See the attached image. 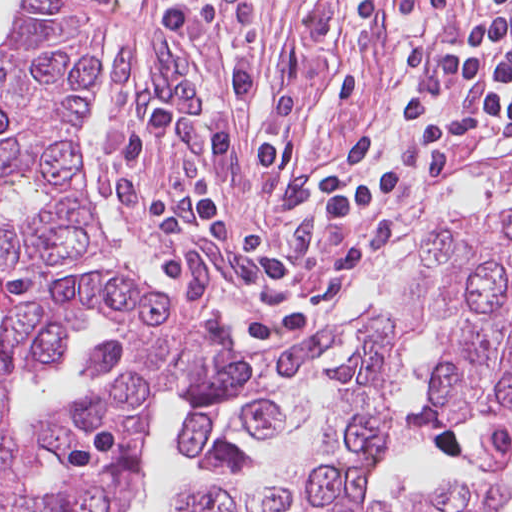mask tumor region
Listing matches in <instances>:
<instances>
[{
  "mask_svg": "<svg viewBox=\"0 0 512 512\" xmlns=\"http://www.w3.org/2000/svg\"><path fill=\"white\" fill-rule=\"evenodd\" d=\"M127 0H24L0 54V204L87 176L82 128Z\"/></svg>",
  "mask_w": 512,
  "mask_h": 512,
  "instance_id": "e687c5a6",
  "label": "tumor region"
}]
</instances>
